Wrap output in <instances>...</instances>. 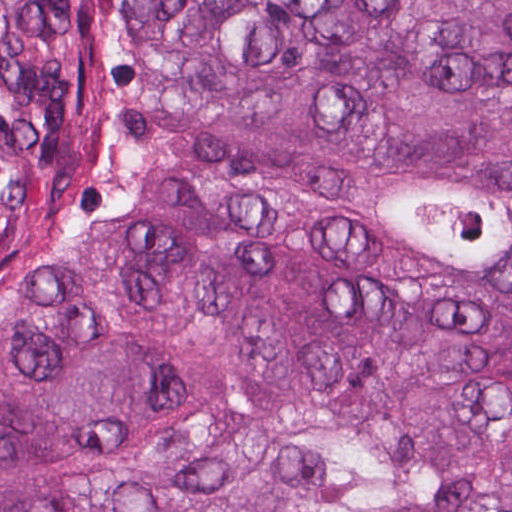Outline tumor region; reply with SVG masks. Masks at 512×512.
<instances>
[{
	"mask_svg": "<svg viewBox=\"0 0 512 512\" xmlns=\"http://www.w3.org/2000/svg\"><path fill=\"white\" fill-rule=\"evenodd\" d=\"M0 512H512V0H0Z\"/></svg>",
	"mask_w": 512,
	"mask_h": 512,
	"instance_id": "1",
	"label": "tumor region"
}]
</instances>
